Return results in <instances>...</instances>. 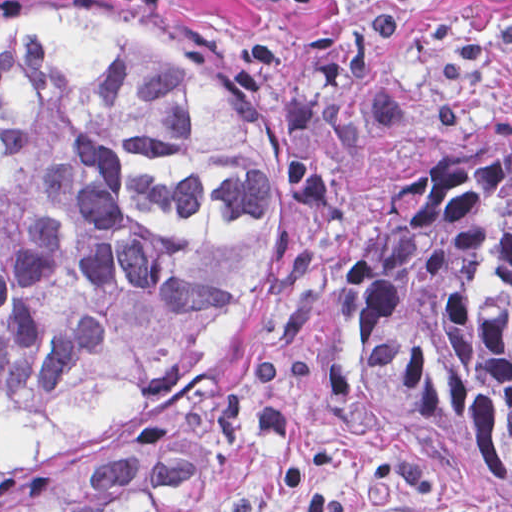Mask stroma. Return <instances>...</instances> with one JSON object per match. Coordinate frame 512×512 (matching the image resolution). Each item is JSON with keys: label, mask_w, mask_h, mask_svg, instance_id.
<instances>
[{"label": "stroma", "mask_w": 512, "mask_h": 512, "mask_svg": "<svg viewBox=\"0 0 512 512\" xmlns=\"http://www.w3.org/2000/svg\"><path fill=\"white\" fill-rule=\"evenodd\" d=\"M60 0H0L1 9ZM121 9L112 0H87ZM130 12V11H128ZM258 104L282 154L274 261L217 377L214 512H512V488L435 431L339 387L363 295L453 156L512 145V0H253L130 12Z\"/></svg>", "instance_id": "35a3bbf8"}]
</instances>
